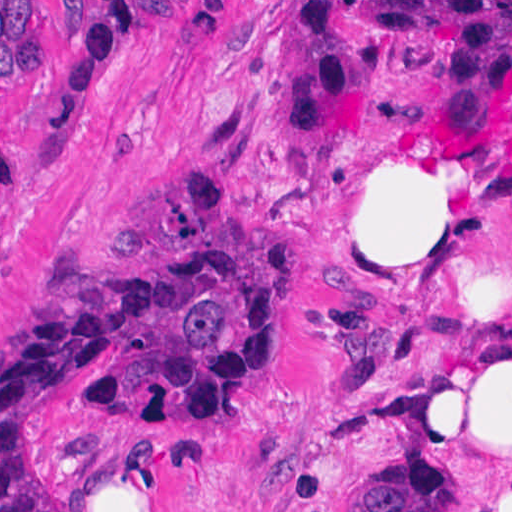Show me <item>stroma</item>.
<instances>
[{
    "mask_svg": "<svg viewBox=\"0 0 512 512\" xmlns=\"http://www.w3.org/2000/svg\"><path fill=\"white\" fill-rule=\"evenodd\" d=\"M36 1L39 70L0 75V364L46 298L161 246L241 245L272 290V328L242 373L157 414L106 406L93 362L30 419L56 512H377L385 463L448 457L483 512L487 451L455 444L413 383L419 352L473 308L439 298H309L303 269L327 193L380 162L493 196L491 250L512 282V93L462 149L429 139L448 100L446 43L377 30L364 136L280 131L279 51L299 1ZM58 1V4L57 2ZM101 1H192L135 16L118 66L62 129L47 108Z\"/></svg>",
    "mask_w": 512,
    "mask_h": 512,
    "instance_id": "obj_1",
    "label": "stroma"
}]
</instances>
